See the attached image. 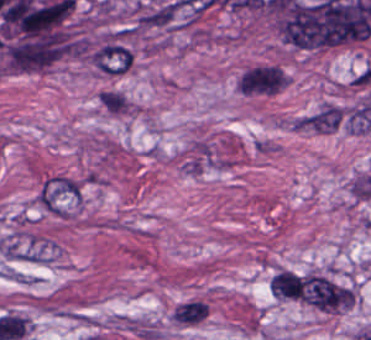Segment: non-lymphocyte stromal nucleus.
<instances>
[{"label": "non-lymphocyte stromal nucleus", "instance_id": "obj_3", "mask_svg": "<svg viewBox=\"0 0 371 340\" xmlns=\"http://www.w3.org/2000/svg\"><path fill=\"white\" fill-rule=\"evenodd\" d=\"M345 119V105L323 100L291 120V125L294 130L330 134L339 130Z\"/></svg>", "mask_w": 371, "mask_h": 340}, {"label": "non-lymphocyte stromal nucleus", "instance_id": "obj_4", "mask_svg": "<svg viewBox=\"0 0 371 340\" xmlns=\"http://www.w3.org/2000/svg\"><path fill=\"white\" fill-rule=\"evenodd\" d=\"M208 309V305L197 299L181 301L174 309L173 320L184 325H194L205 320Z\"/></svg>", "mask_w": 371, "mask_h": 340}, {"label": "non-lymphocyte stromal nucleus", "instance_id": "obj_1", "mask_svg": "<svg viewBox=\"0 0 371 340\" xmlns=\"http://www.w3.org/2000/svg\"><path fill=\"white\" fill-rule=\"evenodd\" d=\"M301 300L327 312L344 310L355 302L350 286L325 274L316 273L301 277Z\"/></svg>", "mask_w": 371, "mask_h": 340}, {"label": "non-lymphocyte stromal nucleus", "instance_id": "obj_2", "mask_svg": "<svg viewBox=\"0 0 371 340\" xmlns=\"http://www.w3.org/2000/svg\"><path fill=\"white\" fill-rule=\"evenodd\" d=\"M34 201L44 211L66 218L82 202L81 184L57 172L46 175L35 192Z\"/></svg>", "mask_w": 371, "mask_h": 340}]
</instances>
